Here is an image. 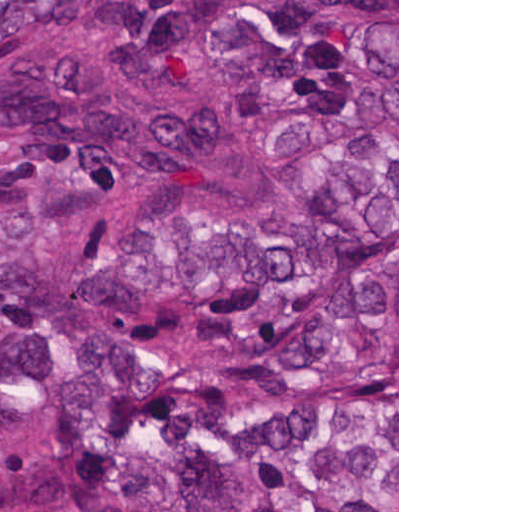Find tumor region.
<instances>
[{"instance_id":"obj_1","label":"tumor region","mask_w":512,"mask_h":512,"mask_svg":"<svg viewBox=\"0 0 512 512\" xmlns=\"http://www.w3.org/2000/svg\"><path fill=\"white\" fill-rule=\"evenodd\" d=\"M198 21L278 202L180 168L228 123L145 120L69 43ZM397 1H0V512L397 508ZM237 512H300L247 509Z\"/></svg>"}]
</instances>
